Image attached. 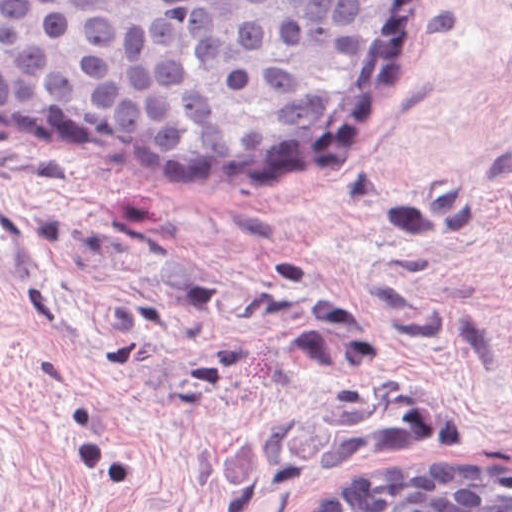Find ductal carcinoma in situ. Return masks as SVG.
Masks as SVG:
<instances>
[{"instance_id":"obj_1","label":"ductal carcinoma in situ","mask_w":512,"mask_h":512,"mask_svg":"<svg viewBox=\"0 0 512 512\" xmlns=\"http://www.w3.org/2000/svg\"><path fill=\"white\" fill-rule=\"evenodd\" d=\"M430 7L0 0V132L108 176L292 196L375 145ZM297 512H512V462L422 459Z\"/></svg>"}]
</instances>
